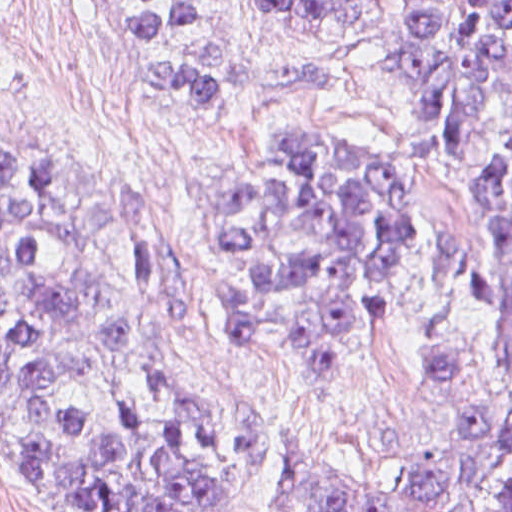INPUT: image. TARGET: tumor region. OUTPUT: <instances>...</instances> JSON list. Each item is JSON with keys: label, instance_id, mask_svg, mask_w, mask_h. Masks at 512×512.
Returning <instances> with one entry per match:
<instances>
[{"label": "tumor region", "instance_id": "tumor-region-1", "mask_svg": "<svg viewBox=\"0 0 512 512\" xmlns=\"http://www.w3.org/2000/svg\"><path fill=\"white\" fill-rule=\"evenodd\" d=\"M136 77L188 130L225 102H275L334 86L329 65L241 69L190 44L135 60L197 18L177 0L145 18H100L148 0H87ZM354 0H263L277 21L341 23ZM384 57L415 108V136L462 146L512 68V0H398ZM10 0H0V15ZM472 169V168H471ZM473 170V169H472ZM473 172L512 249V130ZM421 176L355 137L281 135L224 172L219 258L244 344L310 388L345 399L365 358L402 334L414 294ZM500 330L509 421L420 485L315 446L283 450L302 512H512V305ZM0 399L55 476V512H243L238 404L170 363L147 301L104 243L73 175L0 116Z\"/></svg>", "mask_w": 512, "mask_h": 512}]
</instances>
